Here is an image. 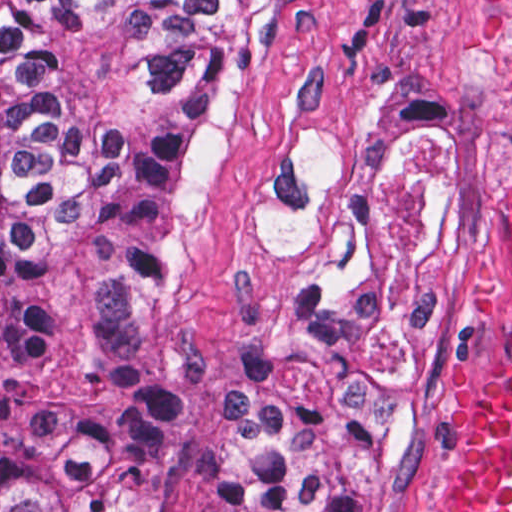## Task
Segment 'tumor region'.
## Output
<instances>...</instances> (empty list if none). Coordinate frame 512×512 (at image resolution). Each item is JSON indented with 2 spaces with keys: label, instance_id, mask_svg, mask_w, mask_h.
<instances>
[{
  "label": "tumor region",
  "instance_id": "e687c5a6",
  "mask_svg": "<svg viewBox=\"0 0 512 512\" xmlns=\"http://www.w3.org/2000/svg\"><path fill=\"white\" fill-rule=\"evenodd\" d=\"M277 0H0V512H141L168 448L219 512H390L439 386V143L376 168L300 286L216 368L156 338L157 265Z\"/></svg>",
  "mask_w": 512,
  "mask_h": 512
}]
</instances>
